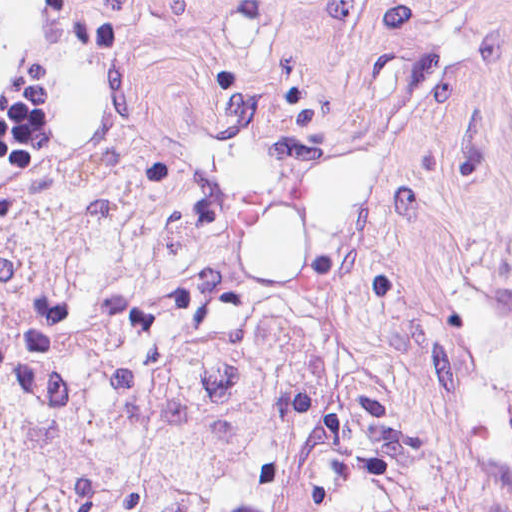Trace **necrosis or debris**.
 <instances>
[{
	"label": "necrosis or debris",
	"instance_id": "obj_1",
	"mask_svg": "<svg viewBox=\"0 0 512 512\" xmlns=\"http://www.w3.org/2000/svg\"><path fill=\"white\" fill-rule=\"evenodd\" d=\"M0 512H512V209L393 241L142 115L0 208Z\"/></svg>",
	"mask_w": 512,
	"mask_h": 512
}]
</instances>
